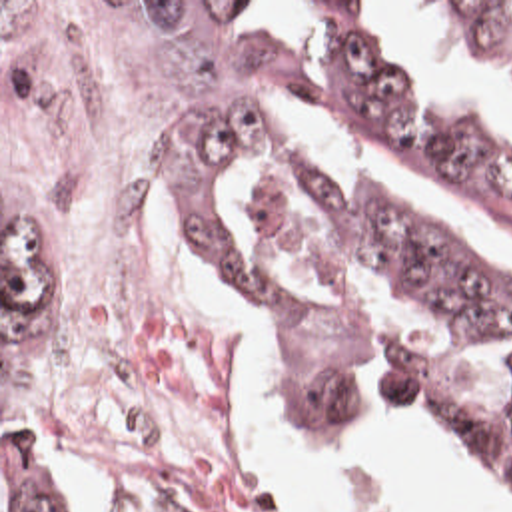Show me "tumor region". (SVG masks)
<instances>
[{
    "instance_id": "1",
    "label": "tumor region",
    "mask_w": 512,
    "mask_h": 512,
    "mask_svg": "<svg viewBox=\"0 0 512 512\" xmlns=\"http://www.w3.org/2000/svg\"><path fill=\"white\" fill-rule=\"evenodd\" d=\"M236 4H222L204 42L178 144L204 272L313 419H403L512 485L511 409L461 393L417 359L359 389L363 325L347 285L383 283L439 329L495 343L512 335V279L377 192L302 168L250 194L240 252L226 202L228 182L278 138L268 114L298 92L512 230V126L435 118L359 34L351 10L365 2H311L333 38L329 70L302 68L276 40H236ZM429 4L512 78V2ZM2 512H56L6 457Z\"/></svg>"
}]
</instances>
